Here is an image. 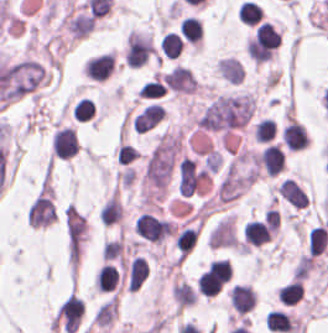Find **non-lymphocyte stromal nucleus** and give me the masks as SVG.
I'll use <instances>...</instances> for the list:
<instances>
[{
  "label": "non-lymphocyte stromal nucleus",
  "mask_w": 328,
  "mask_h": 333,
  "mask_svg": "<svg viewBox=\"0 0 328 333\" xmlns=\"http://www.w3.org/2000/svg\"><path fill=\"white\" fill-rule=\"evenodd\" d=\"M328 245V231L323 226L311 229L308 235V256H318Z\"/></svg>",
  "instance_id": "non-lymphocyte-stromal-nucleus-1"
}]
</instances>
